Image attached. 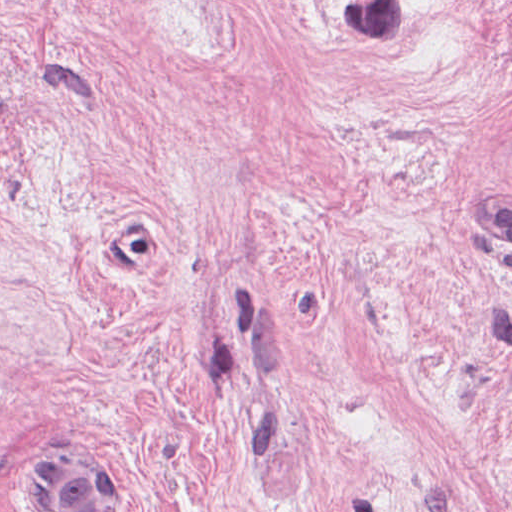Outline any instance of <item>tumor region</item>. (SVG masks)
I'll list each match as a JSON object with an SVG mask.
<instances>
[{
	"instance_id": "obj_1",
	"label": "tumor region",
	"mask_w": 512,
	"mask_h": 512,
	"mask_svg": "<svg viewBox=\"0 0 512 512\" xmlns=\"http://www.w3.org/2000/svg\"><path fill=\"white\" fill-rule=\"evenodd\" d=\"M59 449L44 459L40 479L47 512H123L119 475L82 452L54 455Z\"/></svg>"
}]
</instances>
